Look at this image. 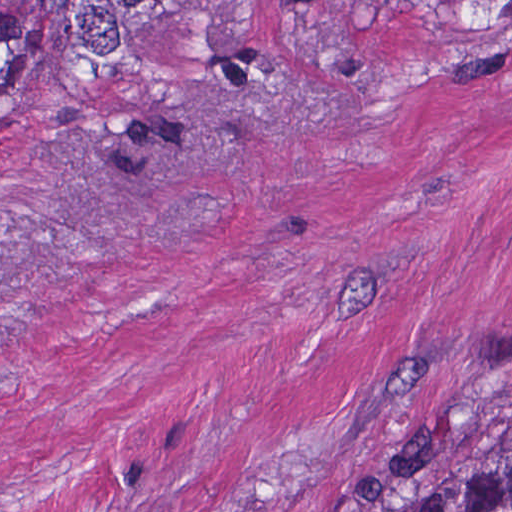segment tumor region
<instances>
[{
  "label": "tumor region",
  "instance_id": "tumor-region-1",
  "mask_svg": "<svg viewBox=\"0 0 512 512\" xmlns=\"http://www.w3.org/2000/svg\"><path fill=\"white\" fill-rule=\"evenodd\" d=\"M174 0H0V101L21 88L86 80ZM442 21L512 23V0H427ZM385 512H512V437L440 448Z\"/></svg>",
  "mask_w": 512,
  "mask_h": 512
}]
</instances>
